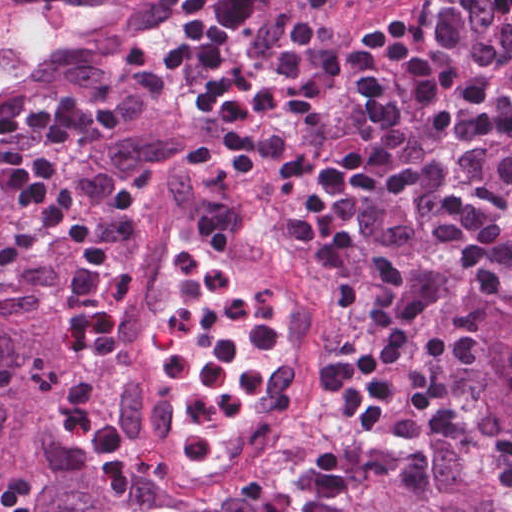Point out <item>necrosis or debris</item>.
<instances>
[{"label":"necrosis or debris","mask_w":512,"mask_h":512,"mask_svg":"<svg viewBox=\"0 0 512 512\" xmlns=\"http://www.w3.org/2000/svg\"><path fill=\"white\" fill-rule=\"evenodd\" d=\"M175 300L150 365L167 400L161 425L134 432L78 365L36 376L41 404L104 476H122L119 512H327L364 478L376 446L345 369L319 362L329 421L276 401L266 380L307 339L295 312L189 240L169 254Z\"/></svg>","instance_id":"4bbe7bcc"}]
</instances>
